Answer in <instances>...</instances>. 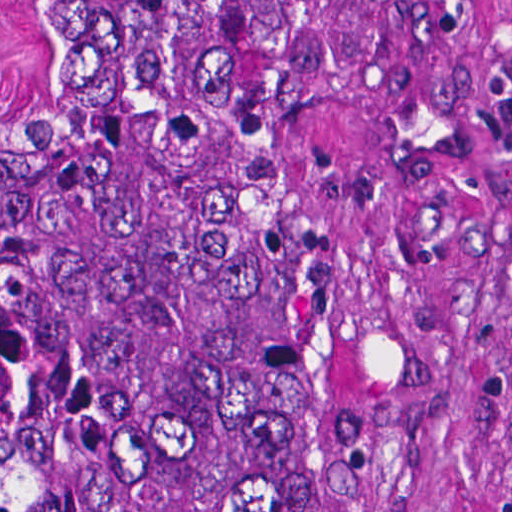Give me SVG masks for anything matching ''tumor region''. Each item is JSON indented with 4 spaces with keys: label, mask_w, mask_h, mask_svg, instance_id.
I'll return each instance as SVG.
<instances>
[{
    "label": "tumor region",
    "mask_w": 512,
    "mask_h": 512,
    "mask_svg": "<svg viewBox=\"0 0 512 512\" xmlns=\"http://www.w3.org/2000/svg\"><path fill=\"white\" fill-rule=\"evenodd\" d=\"M0 112V512H380L347 307L277 232L324 1H42Z\"/></svg>",
    "instance_id": "e687c5a6"
}]
</instances>
